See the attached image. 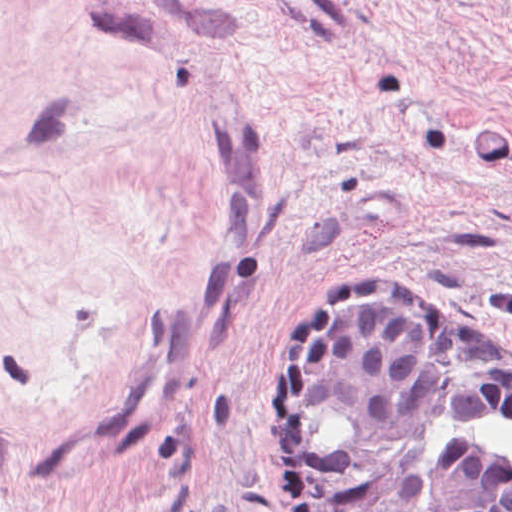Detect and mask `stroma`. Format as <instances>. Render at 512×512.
<instances>
[{
  "instance_id": "stroma-1",
  "label": "stroma",
  "mask_w": 512,
  "mask_h": 512,
  "mask_svg": "<svg viewBox=\"0 0 512 512\" xmlns=\"http://www.w3.org/2000/svg\"><path fill=\"white\" fill-rule=\"evenodd\" d=\"M369 273L512 347V0H0V512H289Z\"/></svg>"
}]
</instances>
